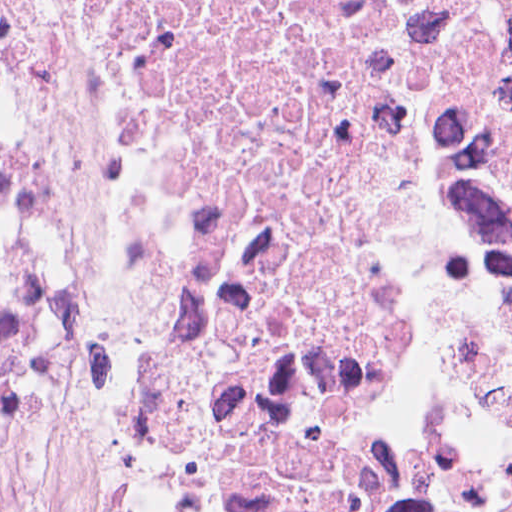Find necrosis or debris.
<instances>
[{
    "label": "necrosis or debris",
    "mask_w": 512,
    "mask_h": 512,
    "mask_svg": "<svg viewBox=\"0 0 512 512\" xmlns=\"http://www.w3.org/2000/svg\"><path fill=\"white\" fill-rule=\"evenodd\" d=\"M0 512H512V0H0Z\"/></svg>",
    "instance_id": "necrosis-or-debris-1"
}]
</instances>
